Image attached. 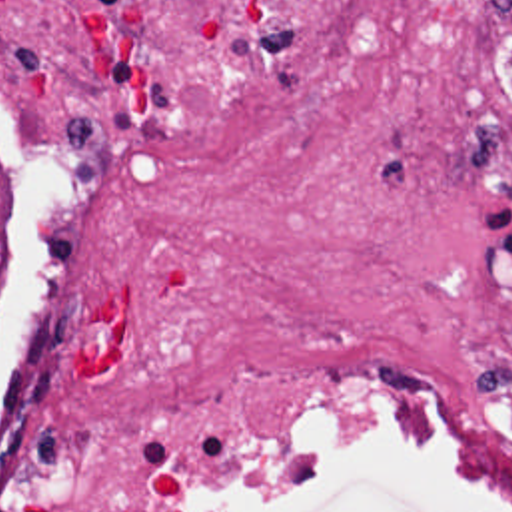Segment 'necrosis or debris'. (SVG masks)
I'll list each match as a JSON object with an SVG mask.
<instances>
[{
  "label": "necrosis or debris",
  "instance_id": "necrosis-or-debris-1",
  "mask_svg": "<svg viewBox=\"0 0 512 512\" xmlns=\"http://www.w3.org/2000/svg\"><path fill=\"white\" fill-rule=\"evenodd\" d=\"M0 107V512H245L361 422L512 512V0H0Z\"/></svg>",
  "mask_w": 512,
  "mask_h": 512
}]
</instances>
